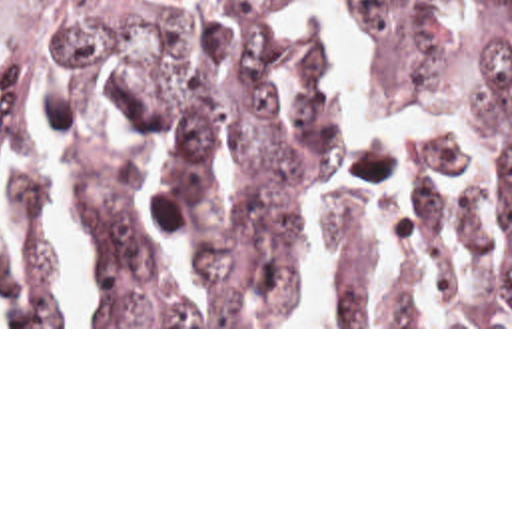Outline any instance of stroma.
I'll use <instances>...</instances> for the list:
<instances>
[{
  "label": "stroma",
  "mask_w": 512,
  "mask_h": 512,
  "mask_svg": "<svg viewBox=\"0 0 512 512\" xmlns=\"http://www.w3.org/2000/svg\"><path fill=\"white\" fill-rule=\"evenodd\" d=\"M0 329H512V325H332V327H284V325H0Z\"/></svg>",
  "instance_id": "stroma-1"
}]
</instances>
